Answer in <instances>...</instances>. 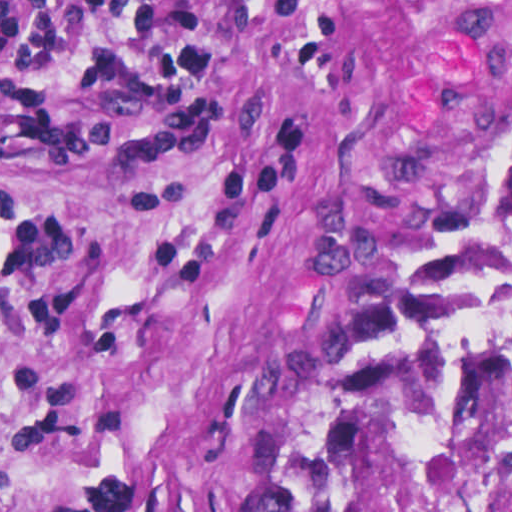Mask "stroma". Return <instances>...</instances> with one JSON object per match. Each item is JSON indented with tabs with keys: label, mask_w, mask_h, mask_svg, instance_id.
<instances>
[{
	"label": "stroma",
	"mask_w": 512,
	"mask_h": 512,
	"mask_svg": "<svg viewBox=\"0 0 512 512\" xmlns=\"http://www.w3.org/2000/svg\"><path fill=\"white\" fill-rule=\"evenodd\" d=\"M511 35L512 0H0V512H303L445 104Z\"/></svg>",
	"instance_id": "obj_1"
}]
</instances>
